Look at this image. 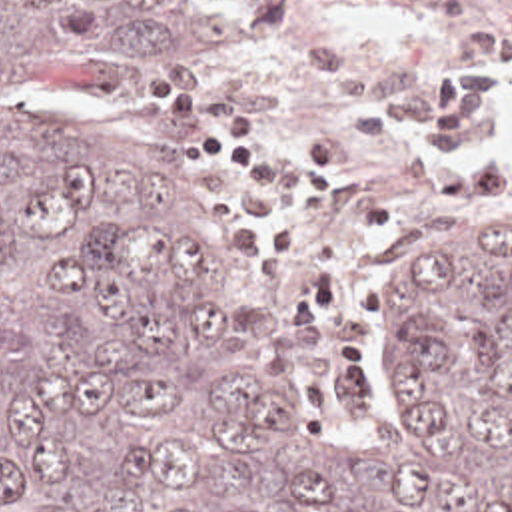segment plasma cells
Here are the masks:
<instances>
[{
  "instance_id": "obj_1",
  "label": "plasma cells",
  "mask_w": 512,
  "mask_h": 512,
  "mask_svg": "<svg viewBox=\"0 0 512 512\" xmlns=\"http://www.w3.org/2000/svg\"><path fill=\"white\" fill-rule=\"evenodd\" d=\"M326 2L250 0V16L262 34H288ZM470 40L494 60H458L432 88H394L370 54L302 42L300 58L350 122L334 146H312L218 76L182 72L147 94V108L182 126L180 172L212 188L242 254L278 293L330 415L376 409L380 232L512 208V68L498 62L512 56V0H494Z\"/></svg>"
}]
</instances>
